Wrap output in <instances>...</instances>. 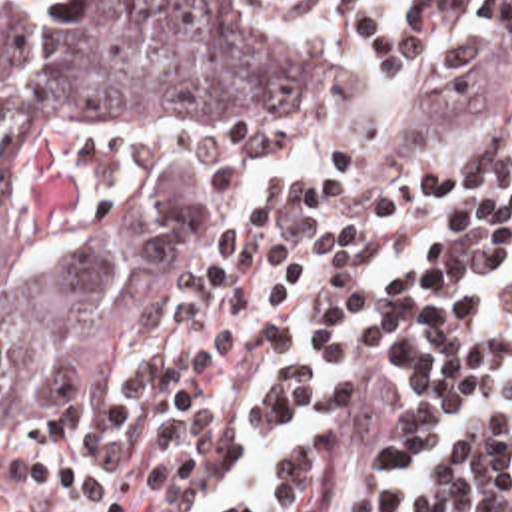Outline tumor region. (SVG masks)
<instances>
[{"mask_svg": "<svg viewBox=\"0 0 512 512\" xmlns=\"http://www.w3.org/2000/svg\"><path fill=\"white\" fill-rule=\"evenodd\" d=\"M323 98L285 28L215 1L0 24V430L127 356L145 322L141 278L33 248L29 170L77 140L237 126Z\"/></svg>", "mask_w": 512, "mask_h": 512, "instance_id": "e687c5a6", "label": "tumor region"}]
</instances>
